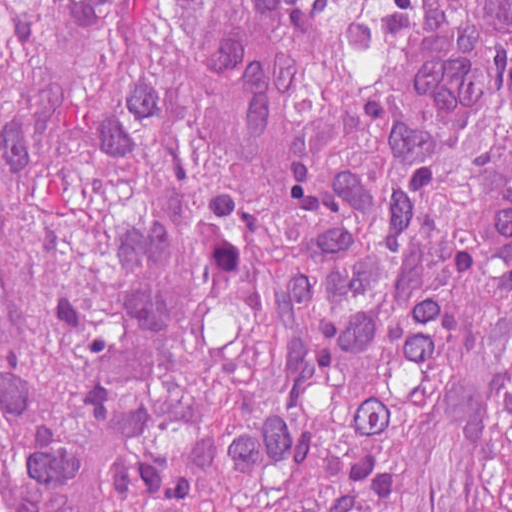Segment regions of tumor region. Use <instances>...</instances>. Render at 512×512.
<instances>
[{
  "mask_svg": "<svg viewBox=\"0 0 512 512\" xmlns=\"http://www.w3.org/2000/svg\"><path fill=\"white\" fill-rule=\"evenodd\" d=\"M0 512H512V0H0Z\"/></svg>",
  "mask_w": 512,
  "mask_h": 512,
  "instance_id": "tumor-region-1",
  "label": "tumor region"
}]
</instances>
